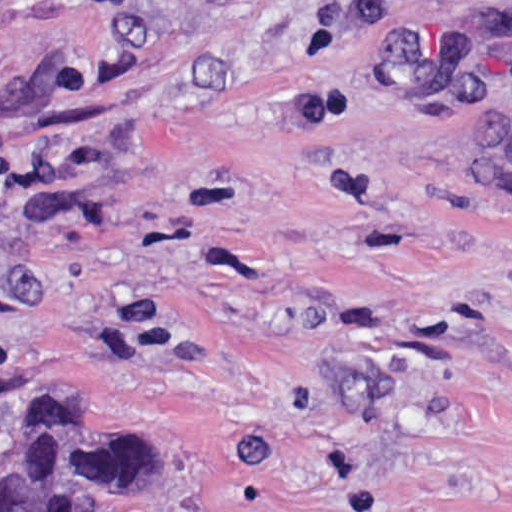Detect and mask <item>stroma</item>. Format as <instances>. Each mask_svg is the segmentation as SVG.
Instances as JSON below:
<instances>
[{
	"label": "stroma",
	"instance_id": "35a3bbf8",
	"mask_svg": "<svg viewBox=\"0 0 512 512\" xmlns=\"http://www.w3.org/2000/svg\"><path fill=\"white\" fill-rule=\"evenodd\" d=\"M79 415L150 512H512V0H0V469Z\"/></svg>",
	"mask_w": 512,
	"mask_h": 512
}]
</instances>
